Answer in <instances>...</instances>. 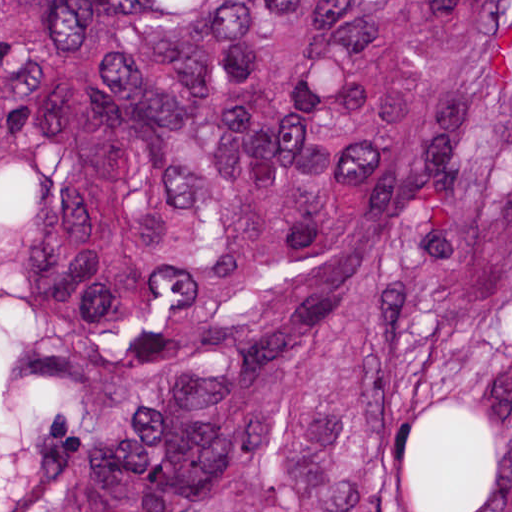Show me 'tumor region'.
I'll return each mask as SVG.
<instances>
[{"mask_svg":"<svg viewBox=\"0 0 512 512\" xmlns=\"http://www.w3.org/2000/svg\"><path fill=\"white\" fill-rule=\"evenodd\" d=\"M0 512H512V0H0Z\"/></svg>","mask_w":512,"mask_h":512,"instance_id":"tumor-region-1","label":"tumor region"}]
</instances>
